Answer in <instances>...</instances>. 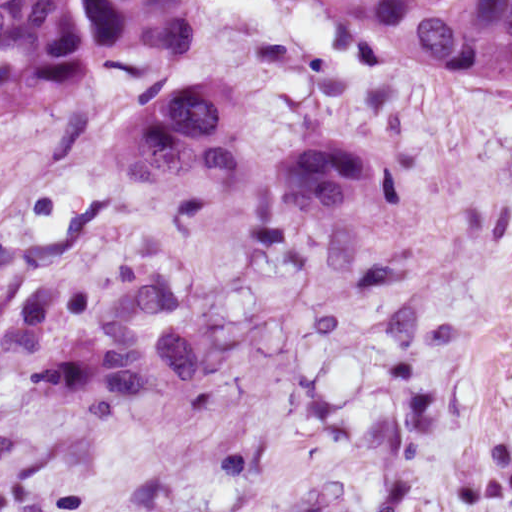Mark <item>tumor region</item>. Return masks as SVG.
<instances>
[{"instance_id": "1", "label": "tumor region", "mask_w": 512, "mask_h": 512, "mask_svg": "<svg viewBox=\"0 0 512 512\" xmlns=\"http://www.w3.org/2000/svg\"><path fill=\"white\" fill-rule=\"evenodd\" d=\"M324 25L350 24L377 64L512 76V0H275ZM223 0H0V125L78 103L99 121L98 154L147 181L237 161L271 204L304 215L345 208L384 176L373 125L304 131L262 90L232 76L212 45ZM158 345L173 384L204 383L205 342L171 284L133 288L102 329L41 372L87 382L111 403L154 390Z\"/></svg>"}]
</instances>
